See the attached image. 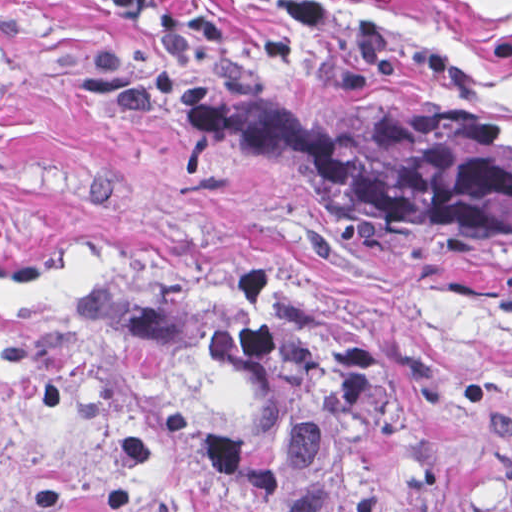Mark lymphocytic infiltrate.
<instances>
[{
    "instance_id": "lymphocytic-infiltrate-1",
    "label": "lymphocytic infiltrate",
    "mask_w": 512,
    "mask_h": 512,
    "mask_svg": "<svg viewBox=\"0 0 512 512\" xmlns=\"http://www.w3.org/2000/svg\"><path fill=\"white\" fill-rule=\"evenodd\" d=\"M96 11L120 20L137 17H158L162 4L160 0H84Z\"/></svg>"
}]
</instances>
